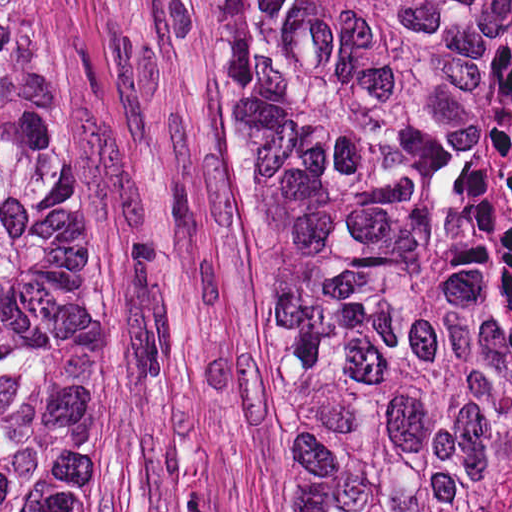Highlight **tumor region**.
<instances>
[{
    "label": "tumor region",
    "instance_id": "tumor-region-1",
    "mask_svg": "<svg viewBox=\"0 0 512 512\" xmlns=\"http://www.w3.org/2000/svg\"><path fill=\"white\" fill-rule=\"evenodd\" d=\"M253 175L298 512H512V0H193ZM0 512H119L90 138L0 0Z\"/></svg>",
    "mask_w": 512,
    "mask_h": 512
}]
</instances>
